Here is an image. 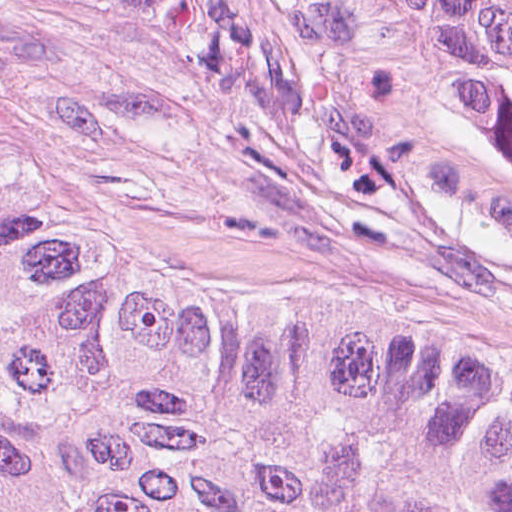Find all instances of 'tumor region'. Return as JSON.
I'll return each mask as SVG.
<instances>
[{"label":"tumor region","mask_w":512,"mask_h":512,"mask_svg":"<svg viewBox=\"0 0 512 512\" xmlns=\"http://www.w3.org/2000/svg\"><path fill=\"white\" fill-rule=\"evenodd\" d=\"M512 173V0H295ZM0 512H512V381L254 316L0 144Z\"/></svg>","instance_id":"e687c5a6"}]
</instances>
